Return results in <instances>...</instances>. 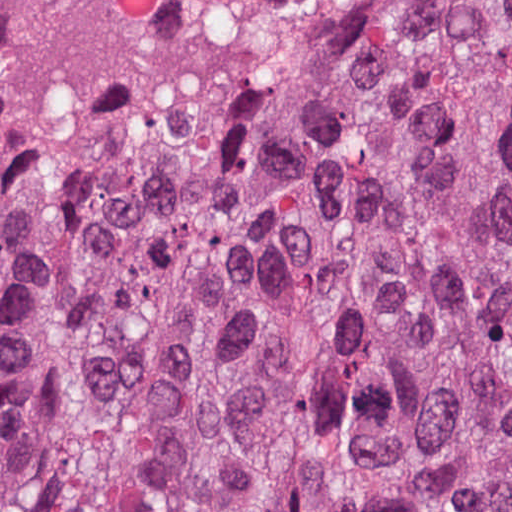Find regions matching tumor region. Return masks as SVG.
I'll use <instances>...</instances> for the list:
<instances>
[{"mask_svg":"<svg viewBox=\"0 0 512 512\" xmlns=\"http://www.w3.org/2000/svg\"><path fill=\"white\" fill-rule=\"evenodd\" d=\"M0 512H512V0H0Z\"/></svg>","mask_w":512,"mask_h":512,"instance_id":"obj_1","label":"tumor region"}]
</instances>
